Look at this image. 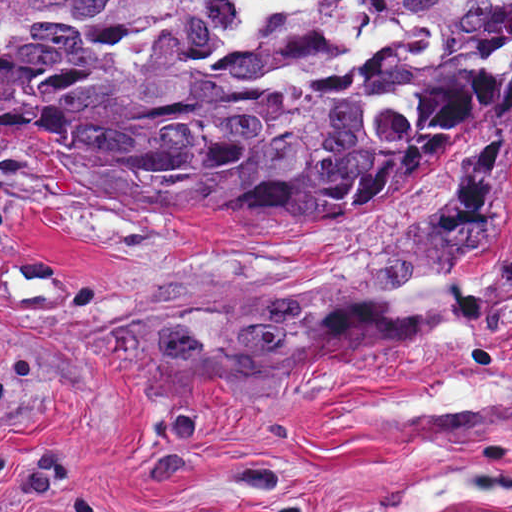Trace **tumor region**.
<instances>
[{
  "instance_id": "tumor-region-1",
  "label": "tumor region",
  "mask_w": 512,
  "mask_h": 512,
  "mask_svg": "<svg viewBox=\"0 0 512 512\" xmlns=\"http://www.w3.org/2000/svg\"><path fill=\"white\" fill-rule=\"evenodd\" d=\"M512 115V0H0V143L250 221L397 195Z\"/></svg>"
}]
</instances>
